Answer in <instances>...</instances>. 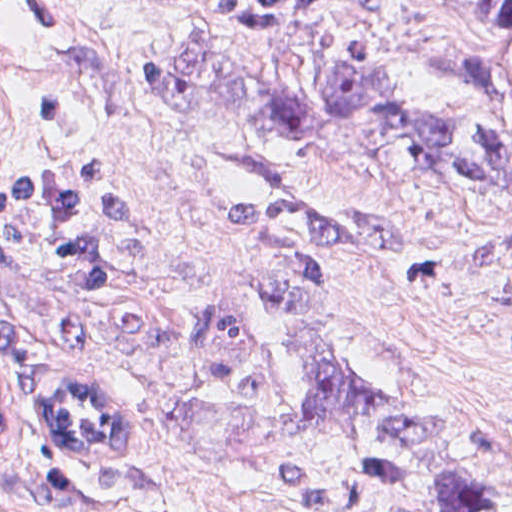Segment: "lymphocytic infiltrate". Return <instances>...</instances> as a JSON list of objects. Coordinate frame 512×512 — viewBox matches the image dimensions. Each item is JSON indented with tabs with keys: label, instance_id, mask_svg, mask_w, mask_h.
Returning a JSON list of instances; mask_svg holds the SVG:
<instances>
[{
	"label": "lymphocytic infiltrate",
	"instance_id": "1",
	"mask_svg": "<svg viewBox=\"0 0 512 512\" xmlns=\"http://www.w3.org/2000/svg\"><path fill=\"white\" fill-rule=\"evenodd\" d=\"M15 252L39 256L46 272L72 291H94L118 279L126 262L127 214L113 173L91 163L77 170L0 176V255ZM0 365L8 379L0 395L1 449L33 414L44 435L49 395L34 411L23 391V342L1 311ZM90 373L98 375L123 460L116 465H76L88 471L124 470L139 454L143 410L114 375Z\"/></svg>",
	"mask_w": 512,
	"mask_h": 512
}]
</instances>
